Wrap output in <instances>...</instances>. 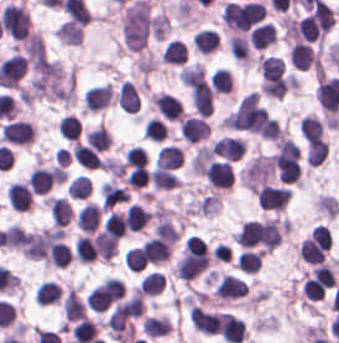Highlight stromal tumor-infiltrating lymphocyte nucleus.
I'll return each instance as SVG.
<instances>
[{
    "instance_id": "3",
    "label": "stromal tumor-infiltrating lymphocyte nucleus",
    "mask_w": 339,
    "mask_h": 343,
    "mask_svg": "<svg viewBox=\"0 0 339 343\" xmlns=\"http://www.w3.org/2000/svg\"><path fill=\"white\" fill-rule=\"evenodd\" d=\"M31 31L27 10L21 3H8L2 10V32L15 41H24Z\"/></svg>"
},
{
    "instance_id": "45",
    "label": "stromal tumor-infiltrating lymphocyte nucleus",
    "mask_w": 339,
    "mask_h": 343,
    "mask_svg": "<svg viewBox=\"0 0 339 343\" xmlns=\"http://www.w3.org/2000/svg\"><path fill=\"white\" fill-rule=\"evenodd\" d=\"M25 233L21 225L12 224L3 232V245L9 249H20Z\"/></svg>"
},
{
    "instance_id": "22",
    "label": "stromal tumor-infiltrating lymphocyte nucleus",
    "mask_w": 339,
    "mask_h": 343,
    "mask_svg": "<svg viewBox=\"0 0 339 343\" xmlns=\"http://www.w3.org/2000/svg\"><path fill=\"white\" fill-rule=\"evenodd\" d=\"M193 42L201 54L207 55L218 49L221 39L216 29L202 28L194 34Z\"/></svg>"
},
{
    "instance_id": "43",
    "label": "stromal tumor-infiltrating lymphocyte nucleus",
    "mask_w": 339,
    "mask_h": 343,
    "mask_svg": "<svg viewBox=\"0 0 339 343\" xmlns=\"http://www.w3.org/2000/svg\"><path fill=\"white\" fill-rule=\"evenodd\" d=\"M66 191L71 200H86L92 191V187L88 178L77 176L70 182Z\"/></svg>"
},
{
    "instance_id": "41",
    "label": "stromal tumor-infiltrating lymphocyte nucleus",
    "mask_w": 339,
    "mask_h": 343,
    "mask_svg": "<svg viewBox=\"0 0 339 343\" xmlns=\"http://www.w3.org/2000/svg\"><path fill=\"white\" fill-rule=\"evenodd\" d=\"M61 136L64 139L78 141L81 136V122L71 115L61 116L59 120Z\"/></svg>"
},
{
    "instance_id": "11",
    "label": "stromal tumor-infiltrating lymphocyte nucleus",
    "mask_w": 339,
    "mask_h": 343,
    "mask_svg": "<svg viewBox=\"0 0 339 343\" xmlns=\"http://www.w3.org/2000/svg\"><path fill=\"white\" fill-rule=\"evenodd\" d=\"M56 167H36L32 170L26 181L35 195H45L57 182Z\"/></svg>"
},
{
    "instance_id": "13",
    "label": "stromal tumor-infiltrating lymphocyte nucleus",
    "mask_w": 339,
    "mask_h": 343,
    "mask_svg": "<svg viewBox=\"0 0 339 343\" xmlns=\"http://www.w3.org/2000/svg\"><path fill=\"white\" fill-rule=\"evenodd\" d=\"M113 96L110 83L90 86L82 94L86 110L93 112L106 107L111 102Z\"/></svg>"
},
{
    "instance_id": "27",
    "label": "stromal tumor-infiltrating lymphocyte nucleus",
    "mask_w": 339,
    "mask_h": 343,
    "mask_svg": "<svg viewBox=\"0 0 339 343\" xmlns=\"http://www.w3.org/2000/svg\"><path fill=\"white\" fill-rule=\"evenodd\" d=\"M60 44L79 45L83 38V30L79 24L64 20L54 31Z\"/></svg>"
},
{
    "instance_id": "26",
    "label": "stromal tumor-infiltrating lymphocyte nucleus",
    "mask_w": 339,
    "mask_h": 343,
    "mask_svg": "<svg viewBox=\"0 0 339 343\" xmlns=\"http://www.w3.org/2000/svg\"><path fill=\"white\" fill-rule=\"evenodd\" d=\"M72 157L85 169H94L99 165L98 152L81 142H74L71 147Z\"/></svg>"
},
{
    "instance_id": "32",
    "label": "stromal tumor-infiltrating lymphocyte nucleus",
    "mask_w": 339,
    "mask_h": 343,
    "mask_svg": "<svg viewBox=\"0 0 339 343\" xmlns=\"http://www.w3.org/2000/svg\"><path fill=\"white\" fill-rule=\"evenodd\" d=\"M325 125L316 116H303L299 125V133L308 142L324 137Z\"/></svg>"
},
{
    "instance_id": "9",
    "label": "stromal tumor-infiltrating lymphocyte nucleus",
    "mask_w": 339,
    "mask_h": 343,
    "mask_svg": "<svg viewBox=\"0 0 339 343\" xmlns=\"http://www.w3.org/2000/svg\"><path fill=\"white\" fill-rule=\"evenodd\" d=\"M150 105L165 119L179 121L182 116V104L168 93L157 92L149 96Z\"/></svg>"
},
{
    "instance_id": "19",
    "label": "stromal tumor-infiltrating lymphocyte nucleus",
    "mask_w": 339,
    "mask_h": 343,
    "mask_svg": "<svg viewBox=\"0 0 339 343\" xmlns=\"http://www.w3.org/2000/svg\"><path fill=\"white\" fill-rule=\"evenodd\" d=\"M258 68L264 82H272L283 76L284 60L275 55H262L258 59Z\"/></svg>"
},
{
    "instance_id": "5",
    "label": "stromal tumor-infiltrating lymphocyte nucleus",
    "mask_w": 339,
    "mask_h": 343,
    "mask_svg": "<svg viewBox=\"0 0 339 343\" xmlns=\"http://www.w3.org/2000/svg\"><path fill=\"white\" fill-rule=\"evenodd\" d=\"M204 176L210 188L231 189L236 173L231 161L214 159L205 169Z\"/></svg>"
},
{
    "instance_id": "20",
    "label": "stromal tumor-infiltrating lymphocyte nucleus",
    "mask_w": 339,
    "mask_h": 343,
    "mask_svg": "<svg viewBox=\"0 0 339 343\" xmlns=\"http://www.w3.org/2000/svg\"><path fill=\"white\" fill-rule=\"evenodd\" d=\"M65 319L70 323L86 315V303L70 286L62 299Z\"/></svg>"
},
{
    "instance_id": "30",
    "label": "stromal tumor-infiltrating lymphocyte nucleus",
    "mask_w": 339,
    "mask_h": 343,
    "mask_svg": "<svg viewBox=\"0 0 339 343\" xmlns=\"http://www.w3.org/2000/svg\"><path fill=\"white\" fill-rule=\"evenodd\" d=\"M61 297V289L56 281H43L34 293V301L46 306L58 303Z\"/></svg>"
},
{
    "instance_id": "16",
    "label": "stromal tumor-infiltrating lymphocyte nucleus",
    "mask_w": 339,
    "mask_h": 343,
    "mask_svg": "<svg viewBox=\"0 0 339 343\" xmlns=\"http://www.w3.org/2000/svg\"><path fill=\"white\" fill-rule=\"evenodd\" d=\"M92 244L95 257L102 263H109L117 253L118 241L103 231L93 234Z\"/></svg>"
},
{
    "instance_id": "18",
    "label": "stromal tumor-infiltrating lymphocyte nucleus",
    "mask_w": 339,
    "mask_h": 343,
    "mask_svg": "<svg viewBox=\"0 0 339 343\" xmlns=\"http://www.w3.org/2000/svg\"><path fill=\"white\" fill-rule=\"evenodd\" d=\"M116 102L128 113H137L140 109L137 86L130 80H123L116 94Z\"/></svg>"
},
{
    "instance_id": "39",
    "label": "stromal tumor-infiltrating lymphocyte nucleus",
    "mask_w": 339,
    "mask_h": 343,
    "mask_svg": "<svg viewBox=\"0 0 339 343\" xmlns=\"http://www.w3.org/2000/svg\"><path fill=\"white\" fill-rule=\"evenodd\" d=\"M111 141L108 130L99 125L88 130L85 136V144L101 152L108 148Z\"/></svg>"
},
{
    "instance_id": "4",
    "label": "stromal tumor-infiltrating lymphocyte nucleus",
    "mask_w": 339,
    "mask_h": 343,
    "mask_svg": "<svg viewBox=\"0 0 339 343\" xmlns=\"http://www.w3.org/2000/svg\"><path fill=\"white\" fill-rule=\"evenodd\" d=\"M36 127L29 121L14 120L4 124L0 130L2 143L18 146H30L34 143Z\"/></svg>"
},
{
    "instance_id": "17",
    "label": "stromal tumor-infiltrating lymphocyte nucleus",
    "mask_w": 339,
    "mask_h": 343,
    "mask_svg": "<svg viewBox=\"0 0 339 343\" xmlns=\"http://www.w3.org/2000/svg\"><path fill=\"white\" fill-rule=\"evenodd\" d=\"M5 194L10 208L15 211L23 212L30 208L32 202V194L24 183H10L5 189Z\"/></svg>"
},
{
    "instance_id": "7",
    "label": "stromal tumor-infiltrating lymphocyte nucleus",
    "mask_w": 339,
    "mask_h": 343,
    "mask_svg": "<svg viewBox=\"0 0 339 343\" xmlns=\"http://www.w3.org/2000/svg\"><path fill=\"white\" fill-rule=\"evenodd\" d=\"M214 292L221 302H230L247 296L248 285L239 277L225 274L217 281Z\"/></svg>"
},
{
    "instance_id": "44",
    "label": "stromal tumor-infiltrating lymphocyte nucleus",
    "mask_w": 339,
    "mask_h": 343,
    "mask_svg": "<svg viewBox=\"0 0 339 343\" xmlns=\"http://www.w3.org/2000/svg\"><path fill=\"white\" fill-rule=\"evenodd\" d=\"M171 29V20L168 12H159L154 14L150 24V32L154 39L162 40L166 37Z\"/></svg>"
},
{
    "instance_id": "10",
    "label": "stromal tumor-infiltrating lymphocyte nucleus",
    "mask_w": 339,
    "mask_h": 343,
    "mask_svg": "<svg viewBox=\"0 0 339 343\" xmlns=\"http://www.w3.org/2000/svg\"><path fill=\"white\" fill-rule=\"evenodd\" d=\"M211 127L205 117L188 116L179 125L180 136L188 143L205 141Z\"/></svg>"
},
{
    "instance_id": "23",
    "label": "stromal tumor-infiltrating lymphocyte nucleus",
    "mask_w": 339,
    "mask_h": 343,
    "mask_svg": "<svg viewBox=\"0 0 339 343\" xmlns=\"http://www.w3.org/2000/svg\"><path fill=\"white\" fill-rule=\"evenodd\" d=\"M143 333L159 337L170 332L172 326L168 316L164 314H150L140 326Z\"/></svg>"
},
{
    "instance_id": "31",
    "label": "stromal tumor-infiltrating lymphocyte nucleus",
    "mask_w": 339,
    "mask_h": 343,
    "mask_svg": "<svg viewBox=\"0 0 339 343\" xmlns=\"http://www.w3.org/2000/svg\"><path fill=\"white\" fill-rule=\"evenodd\" d=\"M165 277L161 272L149 271L138 284L140 294L155 296L163 292Z\"/></svg>"
},
{
    "instance_id": "33",
    "label": "stromal tumor-infiltrating lymphocyte nucleus",
    "mask_w": 339,
    "mask_h": 343,
    "mask_svg": "<svg viewBox=\"0 0 339 343\" xmlns=\"http://www.w3.org/2000/svg\"><path fill=\"white\" fill-rule=\"evenodd\" d=\"M150 217L143 206L131 203L126 213L128 229L137 232L143 230L149 224Z\"/></svg>"
},
{
    "instance_id": "25",
    "label": "stromal tumor-infiltrating lymphocyte nucleus",
    "mask_w": 339,
    "mask_h": 343,
    "mask_svg": "<svg viewBox=\"0 0 339 343\" xmlns=\"http://www.w3.org/2000/svg\"><path fill=\"white\" fill-rule=\"evenodd\" d=\"M72 343H88L96 339L97 324L92 319L80 318L70 331Z\"/></svg>"
},
{
    "instance_id": "42",
    "label": "stromal tumor-infiltrating lymphocyte nucleus",
    "mask_w": 339,
    "mask_h": 343,
    "mask_svg": "<svg viewBox=\"0 0 339 343\" xmlns=\"http://www.w3.org/2000/svg\"><path fill=\"white\" fill-rule=\"evenodd\" d=\"M181 231L168 218H160L154 225V236L162 238L172 243L179 239Z\"/></svg>"
},
{
    "instance_id": "36",
    "label": "stromal tumor-infiltrating lymphocyte nucleus",
    "mask_w": 339,
    "mask_h": 343,
    "mask_svg": "<svg viewBox=\"0 0 339 343\" xmlns=\"http://www.w3.org/2000/svg\"><path fill=\"white\" fill-rule=\"evenodd\" d=\"M127 212L110 211L103 225L108 235L116 238L125 236Z\"/></svg>"
},
{
    "instance_id": "12",
    "label": "stromal tumor-infiltrating lymphocyte nucleus",
    "mask_w": 339,
    "mask_h": 343,
    "mask_svg": "<svg viewBox=\"0 0 339 343\" xmlns=\"http://www.w3.org/2000/svg\"><path fill=\"white\" fill-rule=\"evenodd\" d=\"M221 337L227 343H242L247 337V326L243 318L226 312L222 313Z\"/></svg>"
},
{
    "instance_id": "8",
    "label": "stromal tumor-infiltrating lymphocyte nucleus",
    "mask_w": 339,
    "mask_h": 343,
    "mask_svg": "<svg viewBox=\"0 0 339 343\" xmlns=\"http://www.w3.org/2000/svg\"><path fill=\"white\" fill-rule=\"evenodd\" d=\"M189 320L196 332L206 335L220 333V316L206 309L190 306Z\"/></svg>"
},
{
    "instance_id": "35",
    "label": "stromal tumor-infiltrating lymphocyte nucleus",
    "mask_w": 339,
    "mask_h": 343,
    "mask_svg": "<svg viewBox=\"0 0 339 343\" xmlns=\"http://www.w3.org/2000/svg\"><path fill=\"white\" fill-rule=\"evenodd\" d=\"M152 184L159 190H173L181 187V179L172 171L156 167L152 175Z\"/></svg>"
},
{
    "instance_id": "29",
    "label": "stromal tumor-infiltrating lymphocyte nucleus",
    "mask_w": 339,
    "mask_h": 343,
    "mask_svg": "<svg viewBox=\"0 0 339 343\" xmlns=\"http://www.w3.org/2000/svg\"><path fill=\"white\" fill-rule=\"evenodd\" d=\"M155 160L159 167L176 170L184 162V153L176 146L165 145L159 148Z\"/></svg>"
},
{
    "instance_id": "40",
    "label": "stromal tumor-infiltrating lymphocyte nucleus",
    "mask_w": 339,
    "mask_h": 343,
    "mask_svg": "<svg viewBox=\"0 0 339 343\" xmlns=\"http://www.w3.org/2000/svg\"><path fill=\"white\" fill-rule=\"evenodd\" d=\"M315 208L328 219H335L339 215V201L327 194H320L315 198Z\"/></svg>"
},
{
    "instance_id": "6",
    "label": "stromal tumor-infiltrating lymphocyte nucleus",
    "mask_w": 339,
    "mask_h": 343,
    "mask_svg": "<svg viewBox=\"0 0 339 343\" xmlns=\"http://www.w3.org/2000/svg\"><path fill=\"white\" fill-rule=\"evenodd\" d=\"M291 195L292 189L267 184L257 192L256 199L261 209L283 211Z\"/></svg>"
},
{
    "instance_id": "46",
    "label": "stromal tumor-infiltrating lymphocyte nucleus",
    "mask_w": 339,
    "mask_h": 343,
    "mask_svg": "<svg viewBox=\"0 0 339 343\" xmlns=\"http://www.w3.org/2000/svg\"><path fill=\"white\" fill-rule=\"evenodd\" d=\"M145 137L149 141H163L165 137V125L159 117H151L144 122Z\"/></svg>"
},
{
    "instance_id": "15",
    "label": "stromal tumor-infiltrating lymphocyte nucleus",
    "mask_w": 339,
    "mask_h": 343,
    "mask_svg": "<svg viewBox=\"0 0 339 343\" xmlns=\"http://www.w3.org/2000/svg\"><path fill=\"white\" fill-rule=\"evenodd\" d=\"M102 209L93 202H86L76 213L75 224L82 234H92L98 227Z\"/></svg>"
},
{
    "instance_id": "1",
    "label": "stromal tumor-infiltrating lymphocyte nucleus",
    "mask_w": 339,
    "mask_h": 343,
    "mask_svg": "<svg viewBox=\"0 0 339 343\" xmlns=\"http://www.w3.org/2000/svg\"><path fill=\"white\" fill-rule=\"evenodd\" d=\"M5 85L28 103L71 106L75 101V70L41 49L6 61Z\"/></svg>"
},
{
    "instance_id": "21",
    "label": "stromal tumor-infiltrating lymphocyte nucleus",
    "mask_w": 339,
    "mask_h": 343,
    "mask_svg": "<svg viewBox=\"0 0 339 343\" xmlns=\"http://www.w3.org/2000/svg\"><path fill=\"white\" fill-rule=\"evenodd\" d=\"M252 48L255 50H264L277 41L275 27L272 24H258L250 33Z\"/></svg>"
},
{
    "instance_id": "14",
    "label": "stromal tumor-infiltrating lymphocyte nucleus",
    "mask_w": 339,
    "mask_h": 343,
    "mask_svg": "<svg viewBox=\"0 0 339 343\" xmlns=\"http://www.w3.org/2000/svg\"><path fill=\"white\" fill-rule=\"evenodd\" d=\"M288 61L299 71H308L315 65L316 53L311 44L295 42L288 52Z\"/></svg>"
},
{
    "instance_id": "34",
    "label": "stromal tumor-infiltrating lymphocyte nucleus",
    "mask_w": 339,
    "mask_h": 343,
    "mask_svg": "<svg viewBox=\"0 0 339 343\" xmlns=\"http://www.w3.org/2000/svg\"><path fill=\"white\" fill-rule=\"evenodd\" d=\"M50 215L53 223L59 226L68 225L73 211L70 205L63 198H50Z\"/></svg>"
},
{
    "instance_id": "38",
    "label": "stromal tumor-infiltrating lymphocyte nucleus",
    "mask_w": 339,
    "mask_h": 343,
    "mask_svg": "<svg viewBox=\"0 0 339 343\" xmlns=\"http://www.w3.org/2000/svg\"><path fill=\"white\" fill-rule=\"evenodd\" d=\"M214 91L220 94H231L233 91V75L230 69L219 67L211 74Z\"/></svg>"
},
{
    "instance_id": "24",
    "label": "stromal tumor-infiltrating lymphocyte nucleus",
    "mask_w": 339,
    "mask_h": 343,
    "mask_svg": "<svg viewBox=\"0 0 339 343\" xmlns=\"http://www.w3.org/2000/svg\"><path fill=\"white\" fill-rule=\"evenodd\" d=\"M263 250L244 249L238 252L235 264L237 270L245 273H256L262 263Z\"/></svg>"
},
{
    "instance_id": "2",
    "label": "stromal tumor-infiltrating lymphocyte nucleus",
    "mask_w": 339,
    "mask_h": 343,
    "mask_svg": "<svg viewBox=\"0 0 339 343\" xmlns=\"http://www.w3.org/2000/svg\"><path fill=\"white\" fill-rule=\"evenodd\" d=\"M189 92L191 104L198 116H211L213 112L212 84L199 65H189Z\"/></svg>"
},
{
    "instance_id": "28",
    "label": "stromal tumor-infiltrating lymphocyte nucleus",
    "mask_w": 339,
    "mask_h": 343,
    "mask_svg": "<svg viewBox=\"0 0 339 343\" xmlns=\"http://www.w3.org/2000/svg\"><path fill=\"white\" fill-rule=\"evenodd\" d=\"M160 58L167 65H184L187 60V51L182 42L170 39L164 45Z\"/></svg>"
},
{
    "instance_id": "37",
    "label": "stromal tumor-infiltrating lymphocyte nucleus",
    "mask_w": 339,
    "mask_h": 343,
    "mask_svg": "<svg viewBox=\"0 0 339 343\" xmlns=\"http://www.w3.org/2000/svg\"><path fill=\"white\" fill-rule=\"evenodd\" d=\"M329 153V145L323 140H309L305 160L307 164L319 166L324 162Z\"/></svg>"
}]
</instances>
